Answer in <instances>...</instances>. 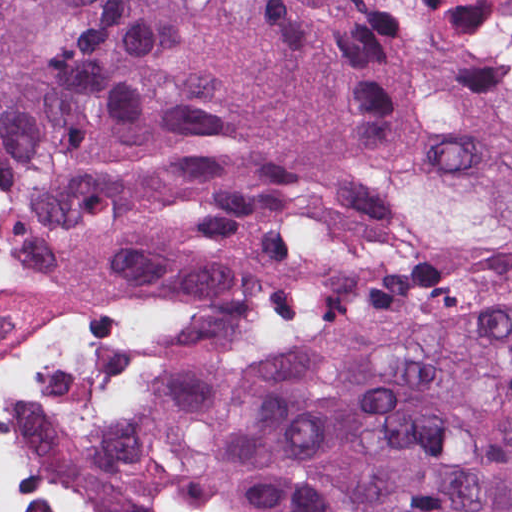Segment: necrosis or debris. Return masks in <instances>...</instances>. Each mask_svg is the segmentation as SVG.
Returning a JSON list of instances; mask_svg holds the SVG:
<instances>
[{
	"instance_id": "4bbe7bcc",
	"label": "necrosis or debris",
	"mask_w": 512,
	"mask_h": 512,
	"mask_svg": "<svg viewBox=\"0 0 512 512\" xmlns=\"http://www.w3.org/2000/svg\"><path fill=\"white\" fill-rule=\"evenodd\" d=\"M0 512H88V414L1 282Z\"/></svg>"
}]
</instances>
